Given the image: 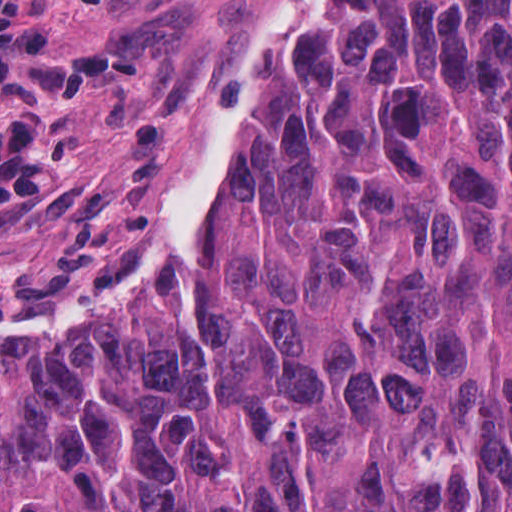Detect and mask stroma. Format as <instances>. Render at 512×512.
Returning a JSON list of instances; mask_svg holds the SVG:
<instances>
[{"label": "stroma", "mask_w": 512, "mask_h": 512, "mask_svg": "<svg viewBox=\"0 0 512 512\" xmlns=\"http://www.w3.org/2000/svg\"><path fill=\"white\" fill-rule=\"evenodd\" d=\"M218 0H0V249L89 215Z\"/></svg>", "instance_id": "1"}]
</instances>
